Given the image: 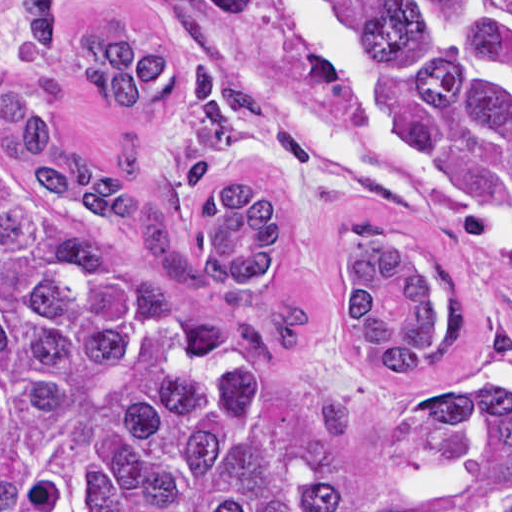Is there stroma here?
Masks as SVG:
<instances>
[{
    "label": "stroma",
    "mask_w": 512,
    "mask_h": 512,
    "mask_svg": "<svg viewBox=\"0 0 512 512\" xmlns=\"http://www.w3.org/2000/svg\"><path fill=\"white\" fill-rule=\"evenodd\" d=\"M21 0H0V92L61 79L64 99L50 117L60 141L105 165L125 134L146 141L143 178L173 241L200 257L210 194L239 180L270 185L278 203L267 293L309 305L311 333L290 350H262L298 428L331 456L374 512H501L485 465L420 429L398 390L362 367L341 327L359 252L382 235H426L440 219L435 196L411 157L406 178H372L344 160L295 115L345 119V88L290 7L242 31L201 16L199 0H64L57 39L69 49L91 32L143 40L176 53L184 76L205 61L261 99V116L236 148L219 156L198 185L161 182L167 159L185 142L178 94L160 110L121 113L86 80L47 66L16 24ZM0 163L17 174L0 146ZM90 217V216H89ZM102 234L140 250L130 228L90 217ZM453 290L482 328L491 362L512 394V238L475 235L450 270Z\"/></svg>",
    "instance_id": "35a3bbf8"
}]
</instances>
